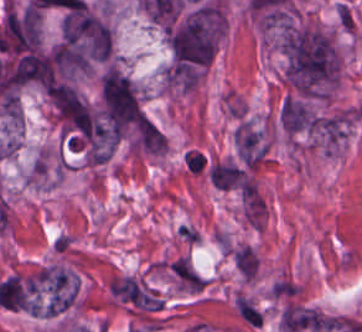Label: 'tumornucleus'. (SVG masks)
Returning <instances> with one entry per match:
<instances>
[{
	"mask_svg": "<svg viewBox=\"0 0 362 332\" xmlns=\"http://www.w3.org/2000/svg\"><path fill=\"white\" fill-rule=\"evenodd\" d=\"M113 34L102 19L86 7L63 12L56 51L82 56H109Z\"/></svg>",
	"mask_w": 362,
	"mask_h": 332,
	"instance_id": "8643909e",
	"label": "tumor nucleus"
},
{
	"mask_svg": "<svg viewBox=\"0 0 362 332\" xmlns=\"http://www.w3.org/2000/svg\"><path fill=\"white\" fill-rule=\"evenodd\" d=\"M285 80L305 95L335 83L340 62L331 38L322 30L290 28L282 45Z\"/></svg>",
	"mask_w": 362,
	"mask_h": 332,
	"instance_id": "2f306a5c",
	"label": "tumor nucleus"
},
{
	"mask_svg": "<svg viewBox=\"0 0 362 332\" xmlns=\"http://www.w3.org/2000/svg\"><path fill=\"white\" fill-rule=\"evenodd\" d=\"M104 117L114 126H123L140 119L141 111L130 79L108 67L99 82Z\"/></svg>",
	"mask_w": 362,
	"mask_h": 332,
	"instance_id": "5ab6c2c4",
	"label": "tumor nucleus"
}]
</instances>
